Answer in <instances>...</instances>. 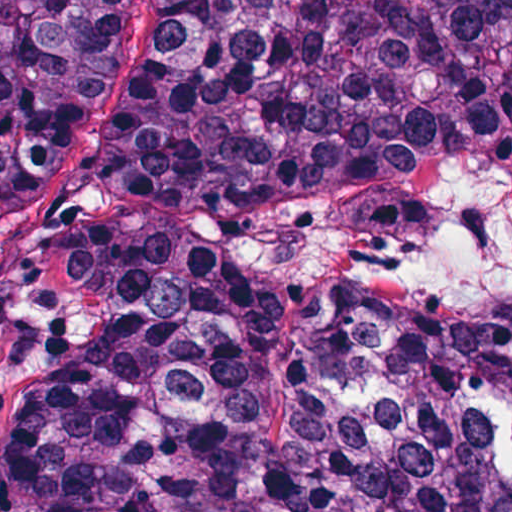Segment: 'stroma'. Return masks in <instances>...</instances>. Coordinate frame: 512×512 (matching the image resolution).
Listing matches in <instances>:
<instances>
[{"label": "stroma", "instance_id": "obj_1", "mask_svg": "<svg viewBox=\"0 0 512 512\" xmlns=\"http://www.w3.org/2000/svg\"><path fill=\"white\" fill-rule=\"evenodd\" d=\"M168 0H126L101 94L38 198L0 177V512L66 419L76 369V292L59 259L127 139L164 46Z\"/></svg>", "mask_w": 512, "mask_h": 512}]
</instances>
